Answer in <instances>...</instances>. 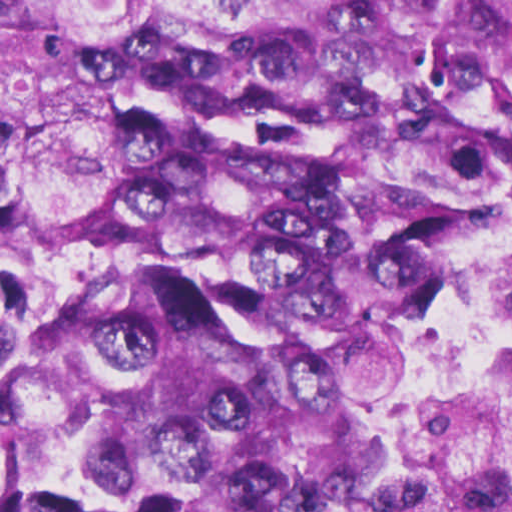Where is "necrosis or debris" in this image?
<instances>
[{
  "label": "necrosis or debris",
  "mask_w": 512,
  "mask_h": 512,
  "mask_svg": "<svg viewBox=\"0 0 512 512\" xmlns=\"http://www.w3.org/2000/svg\"><path fill=\"white\" fill-rule=\"evenodd\" d=\"M434 367L427 512H512V231L488 328Z\"/></svg>",
  "instance_id": "necrosis-or-debris-1"
}]
</instances>
